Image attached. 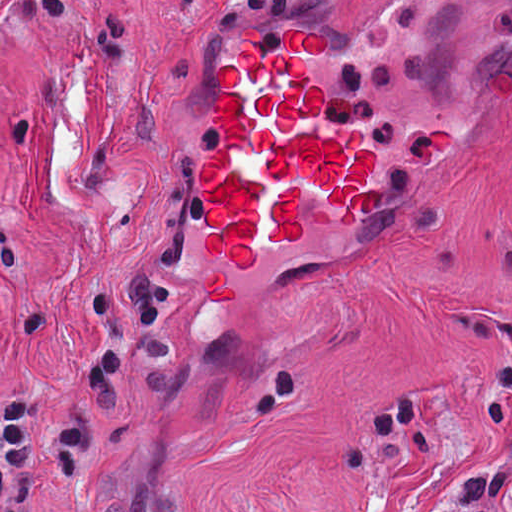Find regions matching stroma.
I'll list each match as a JSON object with an SVG mask.
<instances>
[{
  "instance_id": "35a3bbf8",
  "label": "stroma",
  "mask_w": 512,
  "mask_h": 512,
  "mask_svg": "<svg viewBox=\"0 0 512 512\" xmlns=\"http://www.w3.org/2000/svg\"><path fill=\"white\" fill-rule=\"evenodd\" d=\"M321 30L322 123L361 127L378 188L344 224L214 255L198 164L219 62ZM512 366V0H0V396L83 400L94 479L39 512H466L509 466L476 412ZM415 388L442 446L349 432ZM512 511V486L501 512Z\"/></svg>"
}]
</instances>
